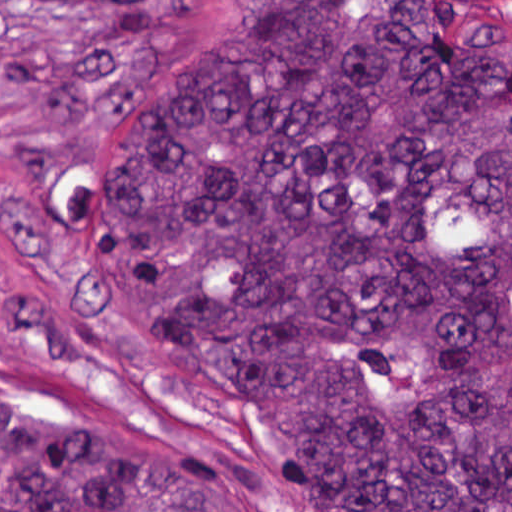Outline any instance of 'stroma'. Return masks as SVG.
<instances>
[{
  "instance_id": "stroma-1",
  "label": "stroma",
  "mask_w": 512,
  "mask_h": 512,
  "mask_svg": "<svg viewBox=\"0 0 512 512\" xmlns=\"http://www.w3.org/2000/svg\"><path fill=\"white\" fill-rule=\"evenodd\" d=\"M236 1H421L512 39V0H0V410L82 444L202 452L255 512H303L251 418L169 356L59 214L126 105L235 23Z\"/></svg>"
}]
</instances>
